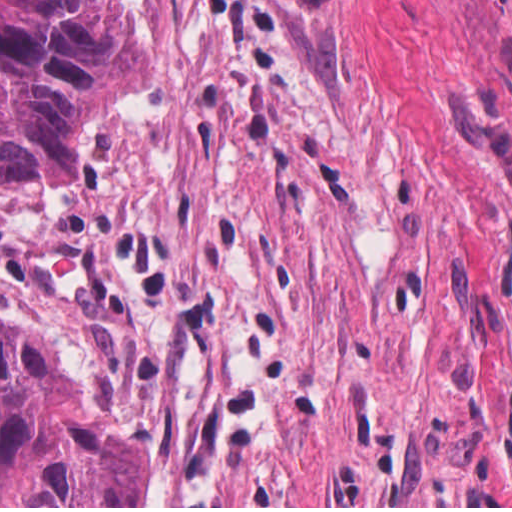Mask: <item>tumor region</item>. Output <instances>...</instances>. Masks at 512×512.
<instances>
[{"mask_svg": "<svg viewBox=\"0 0 512 512\" xmlns=\"http://www.w3.org/2000/svg\"><path fill=\"white\" fill-rule=\"evenodd\" d=\"M145 62L115 7L0 0V193L76 176V135L141 86Z\"/></svg>", "mask_w": 512, "mask_h": 512, "instance_id": "obj_1", "label": "tumor region"}]
</instances>
